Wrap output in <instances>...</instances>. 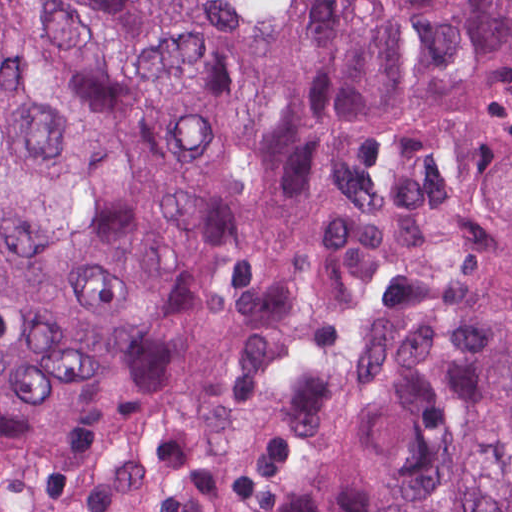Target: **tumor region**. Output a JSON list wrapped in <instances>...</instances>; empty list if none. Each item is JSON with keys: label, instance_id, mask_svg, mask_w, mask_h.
Segmentation results:
<instances>
[{"label": "tumor region", "instance_id": "e687c5a6", "mask_svg": "<svg viewBox=\"0 0 512 512\" xmlns=\"http://www.w3.org/2000/svg\"><path fill=\"white\" fill-rule=\"evenodd\" d=\"M0 512H512V0H0Z\"/></svg>", "mask_w": 512, "mask_h": 512}]
</instances>
